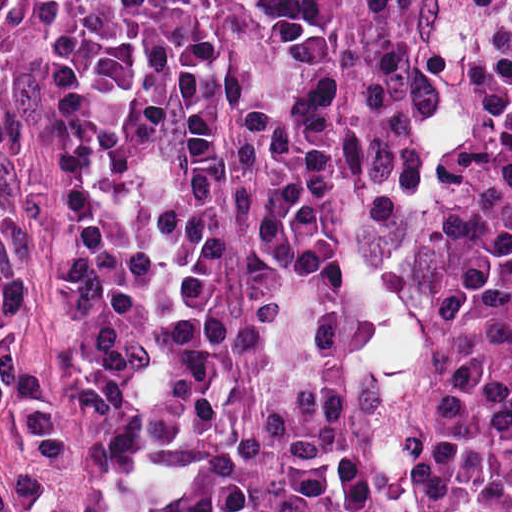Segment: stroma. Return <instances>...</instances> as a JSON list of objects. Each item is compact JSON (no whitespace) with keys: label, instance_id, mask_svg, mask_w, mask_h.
Listing matches in <instances>:
<instances>
[{"label":"stroma","instance_id":"1","mask_svg":"<svg viewBox=\"0 0 512 512\" xmlns=\"http://www.w3.org/2000/svg\"><path fill=\"white\" fill-rule=\"evenodd\" d=\"M473 0H424L422 81L400 189L340 288V394L366 512H437L421 448V353L397 277V201L442 129ZM16 319L52 393L55 351V0L49 36L0 133V328Z\"/></svg>","mask_w":512,"mask_h":512}]
</instances>
